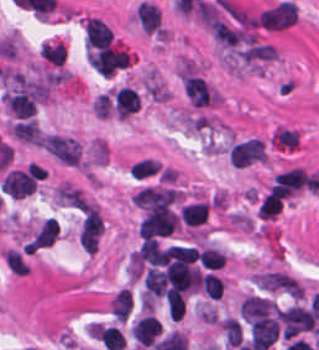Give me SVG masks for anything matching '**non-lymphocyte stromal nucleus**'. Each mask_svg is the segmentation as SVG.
Returning <instances> with one entry per match:
<instances>
[{"instance_id": "3746e769", "label": "non-lymphocyte stromal nucleus", "mask_w": 319, "mask_h": 350, "mask_svg": "<svg viewBox=\"0 0 319 350\" xmlns=\"http://www.w3.org/2000/svg\"><path fill=\"white\" fill-rule=\"evenodd\" d=\"M36 187L30 170L10 169L1 182V192L10 199H23Z\"/></svg>"}, {"instance_id": "616ff342", "label": "non-lymphocyte stromal nucleus", "mask_w": 319, "mask_h": 350, "mask_svg": "<svg viewBox=\"0 0 319 350\" xmlns=\"http://www.w3.org/2000/svg\"><path fill=\"white\" fill-rule=\"evenodd\" d=\"M12 131L14 136L22 142L39 145L41 143L39 127L31 118L12 124Z\"/></svg>"}, {"instance_id": "7c5642bf", "label": "non-lymphocyte stromal nucleus", "mask_w": 319, "mask_h": 350, "mask_svg": "<svg viewBox=\"0 0 319 350\" xmlns=\"http://www.w3.org/2000/svg\"><path fill=\"white\" fill-rule=\"evenodd\" d=\"M183 83L184 91L194 106H207L216 96L202 77L187 75L183 77Z\"/></svg>"}, {"instance_id": "6412c185", "label": "non-lymphocyte stromal nucleus", "mask_w": 319, "mask_h": 350, "mask_svg": "<svg viewBox=\"0 0 319 350\" xmlns=\"http://www.w3.org/2000/svg\"><path fill=\"white\" fill-rule=\"evenodd\" d=\"M56 196L59 200L67 205L75 207L80 210H85L88 207L87 202L76 188L68 185L59 186L56 190Z\"/></svg>"}, {"instance_id": "dd21d789", "label": "non-lymphocyte stromal nucleus", "mask_w": 319, "mask_h": 350, "mask_svg": "<svg viewBox=\"0 0 319 350\" xmlns=\"http://www.w3.org/2000/svg\"><path fill=\"white\" fill-rule=\"evenodd\" d=\"M298 6L289 0H282L260 14L258 20L263 28L283 29L295 23Z\"/></svg>"}, {"instance_id": "fc2b8d12", "label": "non-lymphocyte stromal nucleus", "mask_w": 319, "mask_h": 350, "mask_svg": "<svg viewBox=\"0 0 319 350\" xmlns=\"http://www.w3.org/2000/svg\"><path fill=\"white\" fill-rule=\"evenodd\" d=\"M230 164L245 168L264 160L263 143L256 138L236 142L229 151Z\"/></svg>"}, {"instance_id": "2ac0efb1", "label": "non-lymphocyte stromal nucleus", "mask_w": 319, "mask_h": 350, "mask_svg": "<svg viewBox=\"0 0 319 350\" xmlns=\"http://www.w3.org/2000/svg\"><path fill=\"white\" fill-rule=\"evenodd\" d=\"M136 18L144 32L153 33L159 29L162 21L160 9L154 4L141 3Z\"/></svg>"}, {"instance_id": "0ceb972a", "label": "non-lymphocyte stromal nucleus", "mask_w": 319, "mask_h": 350, "mask_svg": "<svg viewBox=\"0 0 319 350\" xmlns=\"http://www.w3.org/2000/svg\"><path fill=\"white\" fill-rule=\"evenodd\" d=\"M4 257L7 267L15 273L23 276L29 273V268L18 251L8 250Z\"/></svg>"}, {"instance_id": "a72fc3eb", "label": "non-lymphocyte stromal nucleus", "mask_w": 319, "mask_h": 350, "mask_svg": "<svg viewBox=\"0 0 319 350\" xmlns=\"http://www.w3.org/2000/svg\"><path fill=\"white\" fill-rule=\"evenodd\" d=\"M41 140L43 147L61 163L78 164L81 146L73 138L48 134Z\"/></svg>"}, {"instance_id": "9d01c50a", "label": "non-lymphocyte stromal nucleus", "mask_w": 319, "mask_h": 350, "mask_svg": "<svg viewBox=\"0 0 319 350\" xmlns=\"http://www.w3.org/2000/svg\"><path fill=\"white\" fill-rule=\"evenodd\" d=\"M60 232L59 226L51 217L42 225L28 246V251H35L52 245Z\"/></svg>"}, {"instance_id": "81446118", "label": "non-lymphocyte stromal nucleus", "mask_w": 319, "mask_h": 350, "mask_svg": "<svg viewBox=\"0 0 319 350\" xmlns=\"http://www.w3.org/2000/svg\"><path fill=\"white\" fill-rule=\"evenodd\" d=\"M102 232V220L98 211L88 206L82 220L79 243L85 252H94Z\"/></svg>"}]
</instances>
